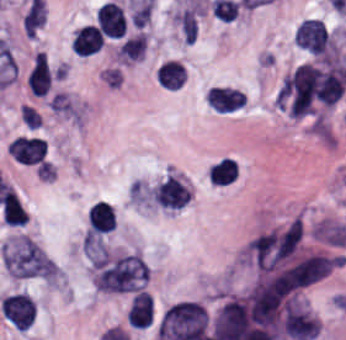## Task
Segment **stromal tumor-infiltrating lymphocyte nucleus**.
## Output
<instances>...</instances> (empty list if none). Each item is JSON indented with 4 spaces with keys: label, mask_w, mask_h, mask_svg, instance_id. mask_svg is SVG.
Masks as SVG:
<instances>
[{
    "label": "stromal tumor-infiltrating lymphocyte nucleus",
    "mask_w": 346,
    "mask_h": 340,
    "mask_svg": "<svg viewBox=\"0 0 346 340\" xmlns=\"http://www.w3.org/2000/svg\"><path fill=\"white\" fill-rule=\"evenodd\" d=\"M208 104L215 111L231 113L246 104L245 93L237 88L214 87L207 92Z\"/></svg>",
    "instance_id": "6"
},
{
    "label": "stromal tumor-infiltrating lymphocyte nucleus",
    "mask_w": 346,
    "mask_h": 340,
    "mask_svg": "<svg viewBox=\"0 0 346 340\" xmlns=\"http://www.w3.org/2000/svg\"><path fill=\"white\" fill-rule=\"evenodd\" d=\"M98 29L106 36L120 39L124 35L126 18L118 3L106 1L97 9Z\"/></svg>",
    "instance_id": "5"
},
{
    "label": "stromal tumor-infiltrating lymphocyte nucleus",
    "mask_w": 346,
    "mask_h": 340,
    "mask_svg": "<svg viewBox=\"0 0 346 340\" xmlns=\"http://www.w3.org/2000/svg\"><path fill=\"white\" fill-rule=\"evenodd\" d=\"M152 315L153 303L149 292L139 291L132 299L128 308V324L145 329L150 325Z\"/></svg>",
    "instance_id": "8"
},
{
    "label": "stromal tumor-infiltrating lymphocyte nucleus",
    "mask_w": 346,
    "mask_h": 340,
    "mask_svg": "<svg viewBox=\"0 0 346 340\" xmlns=\"http://www.w3.org/2000/svg\"><path fill=\"white\" fill-rule=\"evenodd\" d=\"M1 312L14 329L24 331L34 320L35 305L29 294H9L1 302Z\"/></svg>",
    "instance_id": "1"
},
{
    "label": "stromal tumor-infiltrating lymphocyte nucleus",
    "mask_w": 346,
    "mask_h": 340,
    "mask_svg": "<svg viewBox=\"0 0 346 340\" xmlns=\"http://www.w3.org/2000/svg\"><path fill=\"white\" fill-rule=\"evenodd\" d=\"M7 152L16 162L30 166L45 158L47 143L36 136H17L9 144Z\"/></svg>",
    "instance_id": "3"
},
{
    "label": "stromal tumor-infiltrating lymphocyte nucleus",
    "mask_w": 346,
    "mask_h": 340,
    "mask_svg": "<svg viewBox=\"0 0 346 340\" xmlns=\"http://www.w3.org/2000/svg\"><path fill=\"white\" fill-rule=\"evenodd\" d=\"M104 40L97 25H83L75 34L72 48L78 55H93Z\"/></svg>",
    "instance_id": "9"
},
{
    "label": "stromal tumor-infiltrating lymphocyte nucleus",
    "mask_w": 346,
    "mask_h": 340,
    "mask_svg": "<svg viewBox=\"0 0 346 340\" xmlns=\"http://www.w3.org/2000/svg\"><path fill=\"white\" fill-rule=\"evenodd\" d=\"M156 77L162 88L177 90L186 81V72L182 64L167 60L156 70Z\"/></svg>",
    "instance_id": "11"
},
{
    "label": "stromal tumor-infiltrating lymphocyte nucleus",
    "mask_w": 346,
    "mask_h": 340,
    "mask_svg": "<svg viewBox=\"0 0 346 340\" xmlns=\"http://www.w3.org/2000/svg\"><path fill=\"white\" fill-rule=\"evenodd\" d=\"M87 220L94 235L112 232L115 223L113 208L99 200L88 212Z\"/></svg>",
    "instance_id": "10"
},
{
    "label": "stromal tumor-infiltrating lymphocyte nucleus",
    "mask_w": 346,
    "mask_h": 340,
    "mask_svg": "<svg viewBox=\"0 0 346 340\" xmlns=\"http://www.w3.org/2000/svg\"><path fill=\"white\" fill-rule=\"evenodd\" d=\"M241 174V165L237 157L222 155L211 162L206 177L214 187H230L237 182Z\"/></svg>",
    "instance_id": "4"
},
{
    "label": "stromal tumor-infiltrating lymphocyte nucleus",
    "mask_w": 346,
    "mask_h": 340,
    "mask_svg": "<svg viewBox=\"0 0 346 340\" xmlns=\"http://www.w3.org/2000/svg\"><path fill=\"white\" fill-rule=\"evenodd\" d=\"M52 84V71L46 56L36 54L29 76L28 88L35 97H44Z\"/></svg>",
    "instance_id": "7"
},
{
    "label": "stromal tumor-infiltrating lymphocyte nucleus",
    "mask_w": 346,
    "mask_h": 340,
    "mask_svg": "<svg viewBox=\"0 0 346 340\" xmlns=\"http://www.w3.org/2000/svg\"><path fill=\"white\" fill-rule=\"evenodd\" d=\"M298 46L315 53H326L330 44V35L324 20L305 18L296 29Z\"/></svg>",
    "instance_id": "2"
}]
</instances>
